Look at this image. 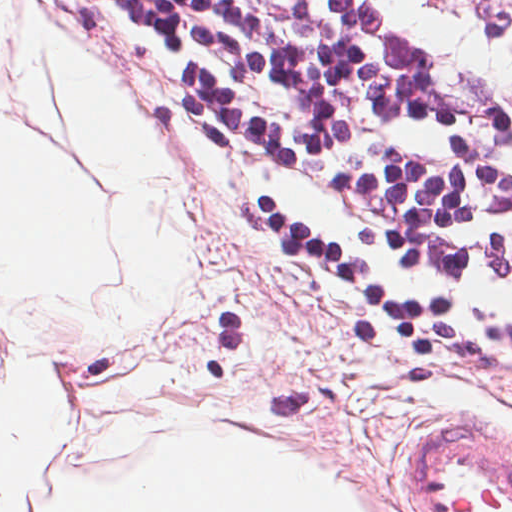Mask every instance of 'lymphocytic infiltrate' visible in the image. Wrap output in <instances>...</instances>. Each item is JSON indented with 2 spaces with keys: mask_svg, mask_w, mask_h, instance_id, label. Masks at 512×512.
Here are the masks:
<instances>
[{
  "mask_svg": "<svg viewBox=\"0 0 512 512\" xmlns=\"http://www.w3.org/2000/svg\"><path fill=\"white\" fill-rule=\"evenodd\" d=\"M229 197L512 456V0H81Z\"/></svg>",
  "mask_w": 512,
  "mask_h": 512,
  "instance_id": "1",
  "label": "lymphocytic infiltrate"
}]
</instances>
